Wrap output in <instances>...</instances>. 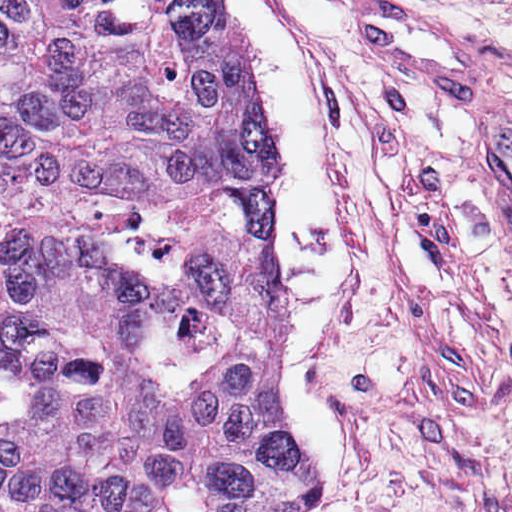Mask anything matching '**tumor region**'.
<instances>
[{
  "mask_svg": "<svg viewBox=\"0 0 512 512\" xmlns=\"http://www.w3.org/2000/svg\"><path fill=\"white\" fill-rule=\"evenodd\" d=\"M274 143L206 0H0V512H282Z\"/></svg>",
  "mask_w": 512,
  "mask_h": 512,
  "instance_id": "obj_1",
  "label": "tumor region"
}]
</instances>
